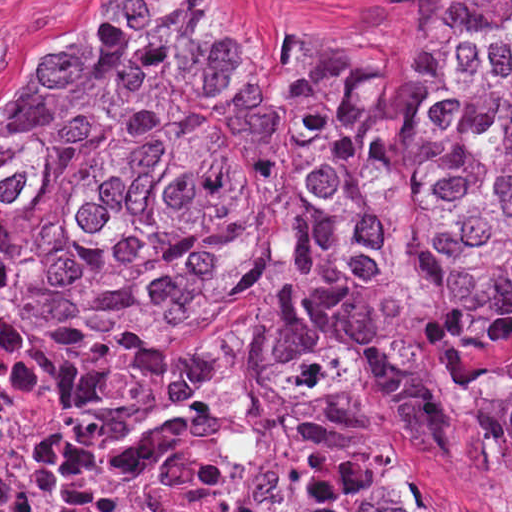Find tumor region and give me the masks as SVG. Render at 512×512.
<instances>
[{
	"mask_svg": "<svg viewBox=\"0 0 512 512\" xmlns=\"http://www.w3.org/2000/svg\"><path fill=\"white\" fill-rule=\"evenodd\" d=\"M374 35L141 0L0 118V512L512 498V0Z\"/></svg>",
	"mask_w": 512,
	"mask_h": 512,
	"instance_id": "obj_1",
	"label": "tumor region"
}]
</instances>
